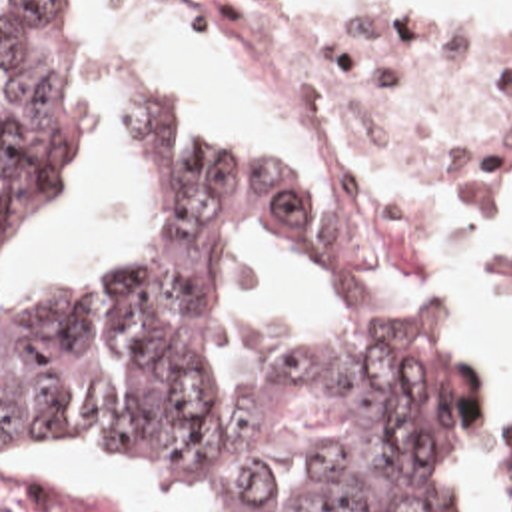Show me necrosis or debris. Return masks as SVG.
I'll list each match as a JSON object with an SVG mask.
<instances>
[{"mask_svg": "<svg viewBox=\"0 0 512 512\" xmlns=\"http://www.w3.org/2000/svg\"><path fill=\"white\" fill-rule=\"evenodd\" d=\"M208 57L304 119L339 251L373 279L407 261L419 197L512 193V49H333L262 0H220Z\"/></svg>", "mask_w": 512, "mask_h": 512, "instance_id": "obj_1", "label": "necrosis or debris"}]
</instances>
